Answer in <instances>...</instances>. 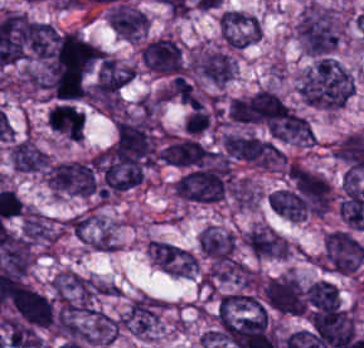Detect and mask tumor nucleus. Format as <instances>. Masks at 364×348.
<instances>
[{
    "label": "tumor nucleus",
    "mask_w": 364,
    "mask_h": 348,
    "mask_svg": "<svg viewBox=\"0 0 364 348\" xmlns=\"http://www.w3.org/2000/svg\"><path fill=\"white\" fill-rule=\"evenodd\" d=\"M105 19L121 38L134 42L145 35L149 24L144 12L120 2L109 9Z\"/></svg>",
    "instance_id": "tumor-nucleus-9"
},
{
    "label": "tumor nucleus",
    "mask_w": 364,
    "mask_h": 348,
    "mask_svg": "<svg viewBox=\"0 0 364 348\" xmlns=\"http://www.w3.org/2000/svg\"><path fill=\"white\" fill-rule=\"evenodd\" d=\"M174 266L181 278H194L197 276V257L187 249L174 261Z\"/></svg>",
    "instance_id": "tumor-nucleus-13"
},
{
    "label": "tumor nucleus",
    "mask_w": 364,
    "mask_h": 348,
    "mask_svg": "<svg viewBox=\"0 0 364 348\" xmlns=\"http://www.w3.org/2000/svg\"><path fill=\"white\" fill-rule=\"evenodd\" d=\"M157 155L164 163L178 167L199 166L211 158L208 148L199 142L170 137Z\"/></svg>",
    "instance_id": "tumor-nucleus-10"
},
{
    "label": "tumor nucleus",
    "mask_w": 364,
    "mask_h": 348,
    "mask_svg": "<svg viewBox=\"0 0 364 348\" xmlns=\"http://www.w3.org/2000/svg\"><path fill=\"white\" fill-rule=\"evenodd\" d=\"M140 57L147 69L159 74L175 75L182 70L179 45L169 36H162L144 44Z\"/></svg>",
    "instance_id": "tumor-nucleus-8"
},
{
    "label": "tumor nucleus",
    "mask_w": 364,
    "mask_h": 348,
    "mask_svg": "<svg viewBox=\"0 0 364 348\" xmlns=\"http://www.w3.org/2000/svg\"><path fill=\"white\" fill-rule=\"evenodd\" d=\"M261 292L268 305L282 315L303 316L305 299L300 283L291 275L269 278Z\"/></svg>",
    "instance_id": "tumor-nucleus-7"
},
{
    "label": "tumor nucleus",
    "mask_w": 364,
    "mask_h": 348,
    "mask_svg": "<svg viewBox=\"0 0 364 348\" xmlns=\"http://www.w3.org/2000/svg\"><path fill=\"white\" fill-rule=\"evenodd\" d=\"M313 259L328 271L356 274L364 261V247L350 232L331 231Z\"/></svg>",
    "instance_id": "tumor-nucleus-3"
},
{
    "label": "tumor nucleus",
    "mask_w": 364,
    "mask_h": 348,
    "mask_svg": "<svg viewBox=\"0 0 364 348\" xmlns=\"http://www.w3.org/2000/svg\"><path fill=\"white\" fill-rule=\"evenodd\" d=\"M44 180L57 192L86 196L97 192L94 168L88 161L56 162L46 169Z\"/></svg>",
    "instance_id": "tumor-nucleus-4"
},
{
    "label": "tumor nucleus",
    "mask_w": 364,
    "mask_h": 348,
    "mask_svg": "<svg viewBox=\"0 0 364 348\" xmlns=\"http://www.w3.org/2000/svg\"><path fill=\"white\" fill-rule=\"evenodd\" d=\"M252 26L250 23L225 10L221 42L240 49L250 46Z\"/></svg>",
    "instance_id": "tumor-nucleus-12"
},
{
    "label": "tumor nucleus",
    "mask_w": 364,
    "mask_h": 348,
    "mask_svg": "<svg viewBox=\"0 0 364 348\" xmlns=\"http://www.w3.org/2000/svg\"><path fill=\"white\" fill-rule=\"evenodd\" d=\"M196 77L215 86H225L235 77V59L231 49L223 46L200 47L193 57Z\"/></svg>",
    "instance_id": "tumor-nucleus-6"
},
{
    "label": "tumor nucleus",
    "mask_w": 364,
    "mask_h": 348,
    "mask_svg": "<svg viewBox=\"0 0 364 348\" xmlns=\"http://www.w3.org/2000/svg\"><path fill=\"white\" fill-rule=\"evenodd\" d=\"M298 98L311 107L337 111L351 98L355 82L336 56H316L296 77Z\"/></svg>",
    "instance_id": "tumor-nucleus-1"
},
{
    "label": "tumor nucleus",
    "mask_w": 364,
    "mask_h": 348,
    "mask_svg": "<svg viewBox=\"0 0 364 348\" xmlns=\"http://www.w3.org/2000/svg\"><path fill=\"white\" fill-rule=\"evenodd\" d=\"M211 120L208 111L202 108H193L187 115L184 123L187 132L197 133L207 128Z\"/></svg>",
    "instance_id": "tumor-nucleus-14"
},
{
    "label": "tumor nucleus",
    "mask_w": 364,
    "mask_h": 348,
    "mask_svg": "<svg viewBox=\"0 0 364 348\" xmlns=\"http://www.w3.org/2000/svg\"><path fill=\"white\" fill-rule=\"evenodd\" d=\"M298 43L307 55H334L343 25L336 12L316 2L307 3L295 21Z\"/></svg>",
    "instance_id": "tumor-nucleus-2"
},
{
    "label": "tumor nucleus",
    "mask_w": 364,
    "mask_h": 348,
    "mask_svg": "<svg viewBox=\"0 0 364 348\" xmlns=\"http://www.w3.org/2000/svg\"><path fill=\"white\" fill-rule=\"evenodd\" d=\"M11 168L18 172L40 175L48 166V156L31 138H18L9 153Z\"/></svg>",
    "instance_id": "tumor-nucleus-11"
},
{
    "label": "tumor nucleus",
    "mask_w": 364,
    "mask_h": 348,
    "mask_svg": "<svg viewBox=\"0 0 364 348\" xmlns=\"http://www.w3.org/2000/svg\"><path fill=\"white\" fill-rule=\"evenodd\" d=\"M222 143L231 158L260 167H270L283 160L282 152L275 143L252 135L229 132Z\"/></svg>",
    "instance_id": "tumor-nucleus-5"
}]
</instances>
